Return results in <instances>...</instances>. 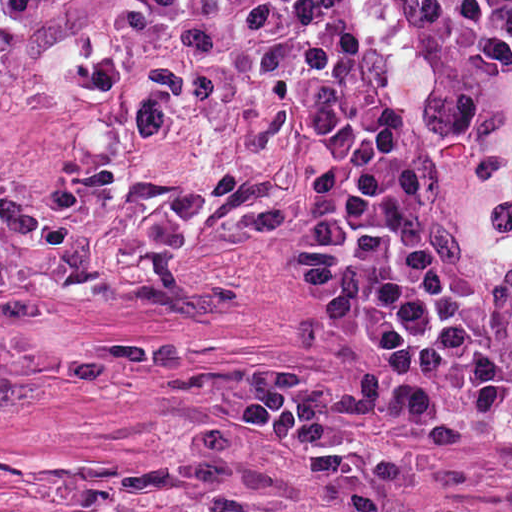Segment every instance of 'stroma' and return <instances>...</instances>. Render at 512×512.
I'll list each match as a JSON object with an SVG mask.
<instances>
[{
	"instance_id": "35a3bbf8",
	"label": "stroma",
	"mask_w": 512,
	"mask_h": 512,
	"mask_svg": "<svg viewBox=\"0 0 512 512\" xmlns=\"http://www.w3.org/2000/svg\"><path fill=\"white\" fill-rule=\"evenodd\" d=\"M97 0L0 18V512H512V411H432L335 477L226 403L351 373L313 186L255 150L63 97ZM426 194L508 157L357 0H322Z\"/></svg>"
}]
</instances>
